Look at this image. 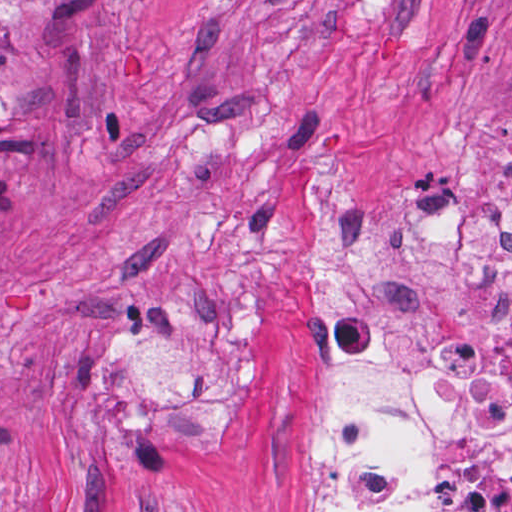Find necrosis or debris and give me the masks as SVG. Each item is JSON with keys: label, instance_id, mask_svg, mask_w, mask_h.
Returning a JSON list of instances; mask_svg holds the SVG:
<instances>
[{"label": "necrosis or debris", "instance_id": "4bbe7bcc", "mask_svg": "<svg viewBox=\"0 0 512 512\" xmlns=\"http://www.w3.org/2000/svg\"><path fill=\"white\" fill-rule=\"evenodd\" d=\"M512 189V146L480 163ZM332 288L312 512H512V217L449 191L392 245L307 212Z\"/></svg>", "mask_w": 512, "mask_h": 512}]
</instances>
